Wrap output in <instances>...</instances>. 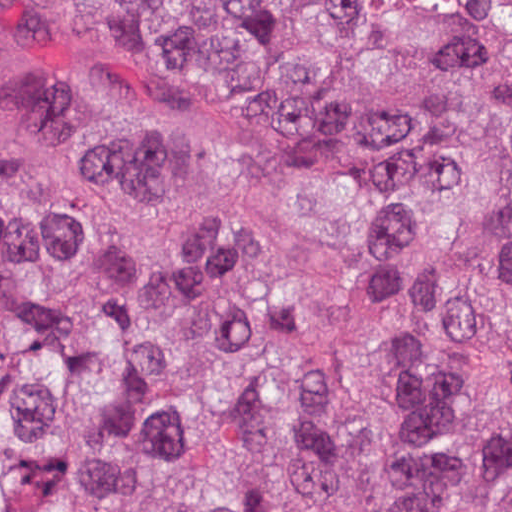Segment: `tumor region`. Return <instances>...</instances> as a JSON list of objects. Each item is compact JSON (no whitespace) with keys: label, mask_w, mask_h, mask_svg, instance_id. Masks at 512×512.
Listing matches in <instances>:
<instances>
[{"label":"tumor region","mask_w":512,"mask_h":512,"mask_svg":"<svg viewBox=\"0 0 512 512\" xmlns=\"http://www.w3.org/2000/svg\"><path fill=\"white\" fill-rule=\"evenodd\" d=\"M0 512H512V0H0Z\"/></svg>","instance_id":"tumor-region-1"}]
</instances>
